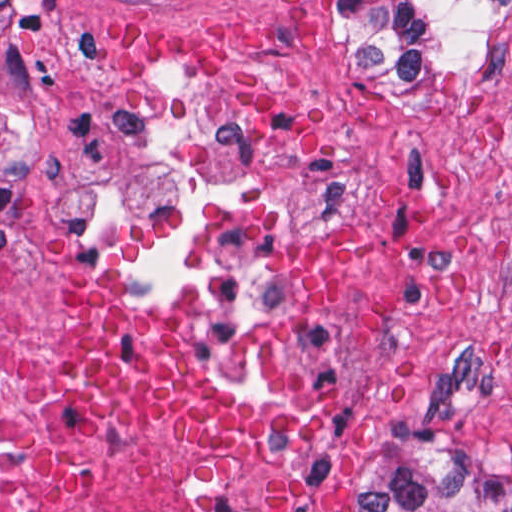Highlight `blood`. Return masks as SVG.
<instances>
[{
	"label": "blood",
	"mask_w": 512,
	"mask_h": 512,
	"mask_svg": "<svg viewBox=\"0 0 512 512\" xmlns=\"http://www.w3.org/2000/svg\"><path fill=\"white\" fill-rule=\"evenodd\" d=\"M62 328L81 394L95 407L187 448L268 463L276 476V512H311L275 466L264 431L208 399L171 350L112 317L73 273Z\"/></svg>",
	"instance_id": "blood-1"
}]
</instances>
